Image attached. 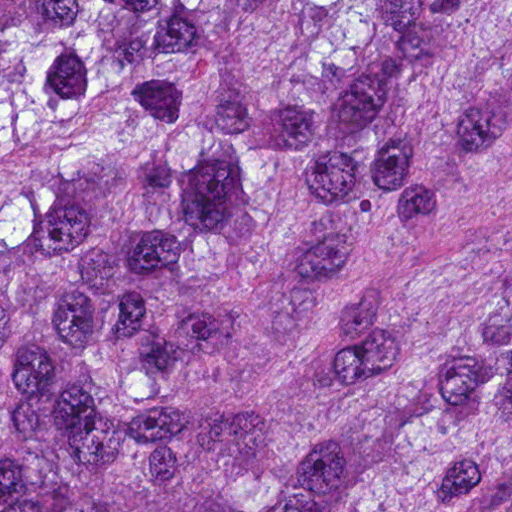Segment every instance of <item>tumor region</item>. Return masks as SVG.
Wrapping results in <instances>:
<instances>
[{
    "label": "tumor region",
    "instance_id": "obj_1",
    "mask_svg": "<svg viewBox=\"0 0 512 512\" xmlns=\"http://www.w3.org/2000/svg\"><path fill=\"white\" fill-rule=\"evenodd\" d=\"M511 102L512 0H0V512H512Z\"/></svg>",
    "mask_w": 512,
    "mask_h": 512
}]
</instances>
